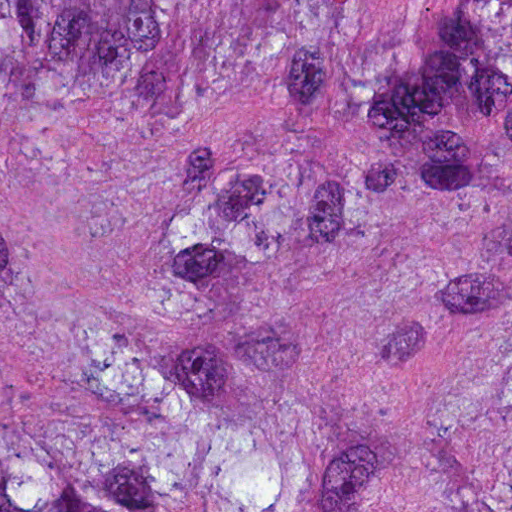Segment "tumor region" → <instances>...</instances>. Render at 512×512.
Wrapping results in <instances>:
<instances>
[{
	"label": "tumor region",
	"mask_w": 512,
	"mask_h": 512,
	"mask_svg": "<svg viewBox=\"0 0 512 512\" xmlns=\"http://www.w3.org/2000/svg\"><path fill=\"white\" fill-rule=\"evenodd\" d=\"M0 512H512V0H0Z\"/></svg>",
	"instance_id": "1"
}]
</instances>
